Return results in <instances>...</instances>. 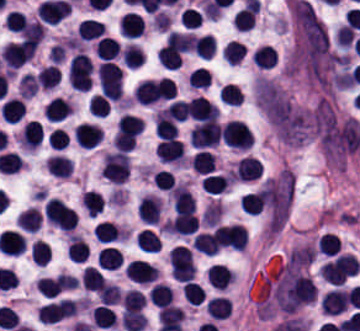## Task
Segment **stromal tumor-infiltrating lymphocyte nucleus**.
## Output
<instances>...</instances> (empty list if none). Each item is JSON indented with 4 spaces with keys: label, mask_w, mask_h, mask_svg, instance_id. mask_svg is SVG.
<instances>
[{
    "label": "stromal tumor-infiltrating lymphocyte nucleus",
    "mask_w": 360,
    "mask_h": 331,
    "mask_svg": "<svg viewBox=\"0 0 360 331\" xmlns=\"http://www.w3.org/2000/svg\"><path fill=\"white\" fill-rule=\"evenodd\" d=\"M147 299L154 306H163L172 300L169 285L161 282H154L149 289Z\"/></svg>",
    "instance_id": "26"
},
{
    "label": "stromal tumor-infiltrating lymphocyte nucleus",
    "mask_w": 360,
    "mask_h": 331,
    "mask_svg": "<svg viewBox=\"0 0 360 331\" xmlns=\"http://www.w3.org/2000/svg\"><path fill=\"white\" fill-rule=\"evenodd\" d=\"M36 89H37V83L33 75L25 72L19 76L17 82V90L20 96L28 99L34 95Z\"/></svg>",
    "instance_id": "44"
},
{
    "label": "stromal tumor-infiltrating lymphocyte nucleus",
    "mask_w": 360,
    "mask_h": 331,
    "mask_svg": "<svg viewBox=\"0 0 360 331\" xmlns=\"http://www.w3.org/2000/svg\"><path fill=\"white\" fill-rule=\"evenodd\" d=\"M105 26L103 22L93 19L91 17H84L80 20L75 28L76 35L81 39L92 40L100 37Z\"/></svg>",
    "instance_id": "15"
},
{
    "label": "stromal tumor-infiltrating lymphocyte nucleus",
    "mask_w": 360,
    "mask_h": 331,
    "mask_svg": "<svg viewBox=\"0 0 360 331\" xmlns=\"http://www.w3.org/2000/svg\"><path fill=\"white\" fill-rule=\"evenodd\" d=\"M117 30L121 36L134 38L143 31V22L137 13L125 11L117 22Z\"/></svg>",
    "instance_id": "11"
},
{
    "label": "stromal tumor-infiltrating lymphocyte nucleus",
    "mask_w": 360,
    "mask_h": 331,
    "mask_svg": "<svg viewBox=\"0 0 360 331\" xmlns=\"http://www.w3.org/2000/svg\"><path fill=\"white\" fill-rule=\"evenodd\" d=\"M253 63L261 68H269L275 64L276 55L272 49L267 45H260L252 51L250 55Z\"/></svg>",
    "instance_id": "30"
},
{
    "label": "stromal tumor-infiltrating lymphocyte nucleus",
    "mask_w": 360,
    "mask_h": 331,
    "mask_svg": "<svg viewBox=\"0 0 360 331\" xmlns=\"http://www.w3.org/2000/svg\"><path fill=\"white\" fill-rule=\"evenodd\" d=\"M181 56L179 51L161 47L159 49L158 63L165 68H179Z\"/></svg>",
    "instance_id": "45"
},
{
    "label": "stromal tumor-infiltrating lymphocyte nucleus",
    "mask_w": 360,
    "mask_h": 331,
    "mask_svg": "<svg viewBox=\"0 0 360 331\" xmlns=\"http://www.w3.org/2000/svg\"><path fill=\"white\" fill-rule=\"evenodd\" d=\"M36 48L37 43L22 40L5 43L0 50L1 61L9 69H16L34 54Z\"/></svg>",
    "instance_id": "1"
},
{
    "label": "stromal tumor-infiltrating lymphocyte nucleus",
    "mask_w": 360,
    "mask_h": 331,
    "mask_svg": "<svg viewBox=\"0 0 360 331\" xmlns=\"http://www.w3.org/2000/svg\"><path fill=\"white\" fill-rule=\"evenodd\" d=\"M37 81L41 89H49L58 84V69L55 64L41 67L37 71Z\"/></svg>",
    "instance_id": "34"
},
{
    "label": "stromal tumor-infiltrating lymphocyte nucleus",
    "mask_w": 360,
    "mask_h": 331,
    "mask_svg": "<svg viewBox=\"0 0 360 331\" xmlns=\"http://www.w3.org/2000/svg\"><path fill=\"white\" fill-rule=\"evenodd\" d=\"M221 101L229 105H240V89L237 83H223L218 88Z\"/></svg>",
    "instance_id": "38"
},
{
    "label": "stromal tumor-infiltrating lymphocyte nucleus",
    "mask_w": 360,
    "mask_h": 331,
    "mask_svg": "<svg viewBox=\"0 0 360 331\" xmlns=\"http://www.w3.org/2000/svg\"><path fill=\"white\" fill-rule=\"evenodd\" d=\"M120 56L122 64L127 68H138L144 59L141 47L130 42L121 50Z\"/></svg>",
    "instance_id": "24"
},
{
    "label": "stromal tumor-infiltrating lymphocyte nucleus",
    "mask_w": 360,
    "mask_h": 331,
    "mask_svg": "<svg viewBox=\"0 0 360 331\" xmlns=\"http://www.w3.org/2000/svg\"><path fill=\"white\" fill-rule=\"evenodd\" d=\"M161 209L160 198L150 195L141 196L139 200L138 218L141 222L157 224Z\"/></svg>",
    "instance_id": "10"
},
{
    "label": "stromal tumor-infiltrating lymphocyte nucleus",
    "mask_w": 360,
    "mask_h": 331,
    "mask_svg": "<svg viewBox=\"0 0 360 331\" xmlns=\"http://www.w3.org/2000/svg\"><path fill=\"white\" fill-rule=\"evenodd\" d=\"M216 47L214 36L200 35L195 36L192 41L194 53L202 59H209Z\"/></svg>",
    "instance_id": "27"
},
{
    "label": "stromal tumor-infiltrating lymphocyte nucleus",
    "mask_w": 360,
    "mask_h": 331,
    "mask_svg": "<svg viewBox=\"0 0 360 331\" xmlns=\"http://www.w3.org/2000/svg\"><path fill=\"white\" fill-rule=\"evenodd\" d=\"M80 283L96 292L102 287V273L93 266H86L81 274Z\"/></svg>",
    "instance_id": "35"
},
{
    "label": "stromal tumor-infiltrating lymphocyte nucleus",
    "mask_w": 360,
    "mask_h": 331,
    "mask_svg": "<svg viewBox=\"0 0 360 331\" xmlns=\"http://www.w3.org/2000/svg\"><path fill=\"white\" fill-rule=\"evenodd\" d=\"M219 125L216 121H202L191 129V144L197 148L214 146L218 142Z\"/></svg>",
    "instance_id": "2"
},
{
    "label": "stromal tumor-infiltrating lymphocyte nucleus",
    "mask_w": 360,
    "mask_h": 331,
    "mask_svg": "<svg viewBox=\"0 0 360 331\" xmlns=\"http://www.w3.org/2000/svg\"><path fill=\"white\" fill-rule=\"evenodd\" d=\"M261 208L260 189L249 191L242 195L241 210L245 213L257 215Z\"/></svg>",
    "instance_id": "36"
},
{
    "label": "stromal tumor-infiltrating lymphocyte nucleus",
    "mask_w": 360,
    "mask_h": 331,
    "mask_svg": "<svg viewBox=\"0 0 360 331\" xmlns=\"http://www.w3.org/2000/svg\"><path fill=\"white\" fill-rule=\"evenodd\" d=\"M209 285L217 290H224L234 279L230 270L221 263H213L206 272Z\"/></svg>",
    "instance_id": "12"
},
{
    "label": "stromal tumor-infiltrating lymphocyte nucleus",
    "mask_w": 360,
    "mask_h": 331,
    "mask_svg": "<svg viewBox=\"0 0 360 331\" xmlns=\"http://www.w3.org/2000/svg\"><path fill=\"white\" fill-rule=\"evenodd\" d=\"M144 295L137 289H129L122 294V312H139L143 307Z\"/></svg>",
    "instance_id": "29"
},
{
    "label": "stromal tumor-infiltrating lymphocyte nucleus",
    "mask_w": 360,
    "mask_h": 331,
    "mask_svg": "<svg viewBox=\"0 0 360 331\" xmlns=\"http://www.w3.org/2000/svg\"><path fill=\"white\" fill-rule=\"evenodd\" d=\"M119 45L111 36H103L94 43V55L101 60H112Z\"/></svg>",
    "instance_id": "23"
},
{
    "label": "stromal tumor-infiltrating lymphocyte nucleus",
    "mask_w": 360,
    "mask_h": 331,
    "mask_svg": "<svg viewBox=\"0 0 360 331\" xmlns=\"http://www.w3.org/2000/svg\"><path fill=\"white\" fill-rule=\"evenodd\" d=\"M120 321L125 331H139L147 322L143 314L134 311L125 312Z\"/></svg>",
    "instance_id": "41"
},
{
    "label": "stromal tumor-infiltrating lymphocyte nucleus",
    "mask_w": 360,
    "mask_h": 331,
    "mask_svg": "<svg viewBox=\"0 0 360 331\" xmlns=\"http://www.w3.org/2000/svg\"><path fill=\"white\" fill-rule=\"evenodd\" d=\"M69 101L60 96H53L43 108V116L49 120H63L71 111Z\"/></svg>",
    "instance_id": "14"
},
{
    "label": "stromal tumor-infiltrating lymphocyte nucleus",
    "mask_w": 360,
    "mask_h": 331,
    "mask_svg": "<svg viewBox=\"0 0 360 331\" xmlns=\"http://www.w3.org/2000/svg\"><path fill=\"white\" fill-rule=\"evenodd\" d=\"M80 199L89 217H96L105 207L102 194L91 189L84 191Z\"/></svg>",
    "instance_id": "18"
},
{
    "label": "stromal tumor-infiltrating lymphocyte nucleus",
    "mask_w": 360,
    "mask_h": 331,
    "mask_svg": "<svg viewBox=\"0 0 360 331\" xmlns=\"http://www.w3.org/2000/svg\"><path fill=\"white\" fill-rule=\"evenodd\" d=\"M134 242L142 252L146 253H156L160 248V241L156 234L145 228L136 233Z\"/></svg>",
    "instance_id": "25"
},
{
    "label": "stromal tumor-infiltrating lymphocyte nucleus",
    "mask_w": 360,
    "mask_h": 331,
    "mask_svg": "<svg viewBox=\"0 0 360 331\" xmlns=\"http://www.w3.org/2000/svg\"><path fill=\"white\" fill-rule=\"evenodd\" d=\"M207 316L216 320L228 318L232 313V301L225 296H212L206 301Z\"/></svg>",
    "instance_id": "13"
},
{
    "label": "stromal tumor-infiltrating lymphocyte nucleus",
    "mask_w": 360,
    "mask_h": 331,
    "mask_svg": "<svg viewBox=\"0 0 360 331\" xmlns=\"http://www.w3.org/2000/svg\"><path fill=\"white\" fill-rule=\"evenodd\" d=\"M72 161L59 154H53L46 159L44 168L57 178H66L71 171Z\"/></svg>",
    "instance_id": "17"
},
{
    "label": "stromal tumor-infiltrating lymphocyte nucleus",
    "mask_w": 360,
    "mask_h": 331,
    "mask_svg": "<svg viewBox=\"0 0 360 331\" xmlns=\"http://www.w3.org/2000/svg\"><path fill=\"white\" fill-rule=\"evenodd\" d=\"M94 237L100 243H108L122 238L119 228L111 221H97Z\"/></svg>",
    "instance_id": "20"
},
{
    "label": "stromal tumor-infiltrating lymphocyte nucleus",
    "mask_w": 360,
    "mask_h": 331,
    "mask_svg": "<svg viewBox=\"0 0 360 331\" xmlns=\"http://www.w3.org/2000/svg\"><path fill=\"white\" fill-rule=\"evenodd\" d=\"M175 120H183L187 114V101L173 99L162 112Z\"/></svg>",
    "instance_id": "47"
},
{
    "label": "stromal tumor-infiltrating lymphocyte nucleus",
    "mask_w": 360,
    "mask_h": 331,
    "mask_svg": "<svg viewBox=\"0 0 360 331\" xmlns=\"http://www.w3.org/2000/svg\"><path fill=\"white\" fill-rule=\"evenodd\" d=\"M187 117L196 121H216L213 104L197 94L187 100Z\"/></svg>",
    "instance_id": "6"
},
{
    "label": "stromal tumor-infiltrating lymphocyte nucleus",
    "mask_w": 360,
    "mask_h": 331,
    "mask_svg": "<svg viewBox=\"0 0 360 331\" xmlns=\"http://www.w3.org/2000/svg\"><path fill=\"white\" fill-rule=\"evenodd\" d=\"M88 108L92 116H106L109 109V100L106 95L94 93Z\"/></svg>",
    "instance_id": "46"
},
{
    "label": "stromal tumor-infiltrating lymphocyte nucleus",
    "mask_w": 360,
    "mask_h": 331,
    "mask_svg": "<svg viewBox=\"0 0 360 331\" xmlns=\"http://www.w3.org/2000/svg\"><path fill=\"white\" fill-rule=\"evenodd\" d=\"M319 307L327 315H340L346 310L344 289L332 288L319 298Z\"/></svg>",
    "instance_id": "7"
},
{
    "label": "stromal tumor-infiltrating lymphocyte nucleus",
    "mask_w": 360,
    "mask_h": 331,
    "mask_svg": "<svg viewBox=\"0 0 360 331\" xmlns=\"http://www.w3.org/2000/svg\"><path fill=\"white\" fill-rule=\"evenodd\" d=\"M154 132L159 138H170L177 134L176 123L172 117L155 115Z\"/></svg>",
    "instance_id": "32"
},
{
    "label": "stromal tumor-infiltrating lymphocyte nucleus",
    "mask_w": 360,
    "mask_h": 331,
    "mask_svg": "<svg viewBox=\"0 0 360 331\" xmlns=\"http://www.w3.org/2000/svg\"><path fill=\"white\" fill-rule=\"evenodd\" d=\"M219 245L213 232H200L192 242V249L200 254L216 255Z\"/></svg>",
    "instance_id": "19"
},
{
    "label": "stromal tumor-infiltrating lymphocyte nucleus",
    "mask_w": 360,
    "mask_h": 331,
    "mask_svg": "<svg viewBox=\"0 0 360 331\" xmlns=\"http://www.w3.org/2000/svg\"><path fill=\"white\" fill-rule=\"evenodd\" d=\"M155 153L163 163H180L184 155L180 140L174 138H162L155 148Z\"/></svg>",
    "instance_id": "9"
},
{
    "label": "stromal tumor-infiltrating lymphocyte nucleus",
    "mask_w": 360,
    "mask_h": 331,
    "mask_svg": "<svg viewBox=\"0 0 360 331\" xmlns=\"http://www.w3.org/2000/svg\"><path fill=\"white\" fill-rule=\"evenodd\" d=\"M262 164L255 156L244 155L234 164L232 176L239 180H254L259 178Z\"/></svg>",
    "instance_id": "8"
},
{
    "label": "stromal tumor-infiltrating lymphocyte nucleus",
    "mask_w": 360,
    "mask_h": 331,
    "mask_svg": "<svg viewBox=\"0 0 360 331\" xmlns=\"http://www.w3.org/2000/svg\"><path fill=\"white\" fill-rule=\"evenodd\" d=\"M17 227L22 231H36L39 225L38 211L32 206L17 215Z\"/></svg>",
    "instance_id": "31"
},
{
    "label": "stromal tumor-infiltrating lymphocyte nucleus",
    "mask_w": 360,
    "mask_h": 331,
    "mask_svg": "<svg viewBox=\"0 0 360 331\" xmlns=\"http://www.w3.org/2000/svg\"><path fill=\"white\" fill-rule=\"evenodd\" d=\"M121 291L116 284L103 283L98 294L97 299L100 305H113L119 301Z\"/></svg>",
    "instance_id": "37"
},
{
    "label": "stromal tumor-infiltrating lymphocyte nucleus",
    "mask_w": 360,
    "mask_h": 331,
    "mask_svg": "<svg viewBox=\"0 0 360 331\" xmlns=\"http://www.w3.org/2000/svg\"><path fill=\"white\" fill-rule=\"evenodd\" d=\"M191 166L196 174H209L213 171L216 162L211 152L199 151L192 159Z\"/></svg>",
    "instance_id": "28"
},
{
    "label": "stromal tumor-infiltrating lymphocyte nucleus",
    "mask_w": 360,
    "mask_h": 331,
    "mask_svg": "<svg viewBox=\"0 0 360 331\" xmlns=\"http://www.w3.org/2000/svg\"><path fill=\"white\" fill-rule=\"evenodd\" d=\"M101 138L102 130L97 124L81 121L74 126L73 139L85 148L96 147Z\"/></svg>",
    "instance_id": "4"
},
{
    "label": "stromal tumor-infiltrating lymphocyte nucleus",
    "mask_w": 360,
    "mask_h": 331,
    "mask_svg": "<svg viewBox=\"0 0 360 331\" xmlns=\"http://www.w3.org/2000/svg\"><path fill=\"white\" fill-rule=\"evenodd\" d=\"M30 255L33 263L43 267L51 256V250L48 244L36 238L30 244Z\"/></svg>",
    "instance_id": "33"
},
{
    "label": "stromal tumor-infiltrating lymphocyte nucleus",
    "mask_w": 360,
    "mask_h": 331,
    "mask_svg": "<svg viewBox=\"0 0 360 331\" xmlns=\"http://www.w3.org/2000/svg\"><path fill=\"white\" fill-rule=\"evenodd\" d=\"M245 45L238 40H231L223 47L222 58L229 64H237L244 55Z\"/></svg>",
    "instance_id": "40"
},
{
    "label": "stromal tumor-infiltrating lymphocyte nucleus",
    "mask_w": 360,
    "mask_h": 331,
    "mask_svg": "<svg viewBox=\"0 0 360 331\" xmlns=\"http://www.w3.org/2000/svg\"><path fill=\"white\" fill-rule=\"evenodd\" d=\"M222 213V203L217 201L208 203L201 214V225L213 226Z\"/></svg>",
    "instance_id": "43"
},
{
    "label": "stromal tumor-infiltrating lymphocyte nucleus",
    "mask_w": 360,
    "mask_h": 331,
    "mask_svg": "<svg viewBox=\"0 0 360 331\" xmlns=\"http://www.w3.org/2000/svg\"><path fill=\"white\" fill-rule=\"evenodd\" d=\"M89 246L84 238L69 235L67 242V258L71 262H80L87 257Z\"/></svg>",
    "instance_id": "21"
},
{
    "label": "stromal tumor-infiltrating lymphocyte nucleus",
    "mask_w": 360,
    "mask_h": 331,
    "mask_svg": "<svg viewBox=\"0 0 360 331\" xmlns=\"http://www.w3.org/2000/svg\"><path fill=\"white\" fill-rule=\"evenodd\" d=\"M96 262L104 269H114L120 266L122 254L116 247H102L96 254Z\"/></svg>",
    "instance_id": "22"
},
{
    "label": "stromal tumor-infiltrating lymphocyte nucleus",
    "mask_w": 360,
    "mask_h": 331,
    "mask_svg": "<svg viewBox=\"0 0 360 331\" xmlns=\"http://www.w3.org/2000/svg\"><path fill=\"white\" fill-rule=\"evenodd\" d=\"M123 271L127 279L139 284H148L154 281L158 274L151 264L139 259H132L125 265Z\"/></svg>",
    "instance_id": "3"
},
{
    "label": "stromal tumor-infiltrating lymphocyte nucleus",
    "mask_w": 360,
    "mask_h": 331,
    "mask_svg": "<svg viewBox=\"0 0 360 331\" xmlns=\"http://www.w3.org/2000/svg\"><path fill=\"white\" fill-rule=\"evenodd\" d=\"M48 146L53 151H61L68 146L69 136L61 127H54L47 136Z\"/></svg>",
    "instance_id": "42"
},
{
    "label": "stromal tumor-infiltrating lymphocyte nucleus",
    "mask_w": 360,
    "mask_h": 331,
    "mask_svg": "<svg viewBox=\"0 0 360 331\" xmlns=\"http://www.w3.org/2000/svg\"><path fill=\"white\" fill-rule=\"evenodd\" d=\"M209 85V74L203 68H197L189 72V86L194 88H206Z\"/></svg>",
    "instance_id": "48"
},
{
    "label": "stromal tumor-infiltrating lymphocyte nucleus",
    "mask_w": 360,
    "mask_h": 331,
    "mask_svg": "<svg viewBox=\"0 0 360 331\" xmlns=\"http://www.w3.org/2000/svg\"><path fill=\"white\" fill-rule=\"evenodd\" d=\"M232 179L228 172L205 175L202 190L207 194H221L230 185Z\"/></svg>",
    "instance_id": "16"
},
{
    "label": "stromal tumor-infiltrating lymphocyte nucleus",
    "mask_w": 360,
    "mask_h": 331,
    "mask_svg": "<svg viewBox=\"0 0 360 331\" xmlns=\"http://www.w3.org/2000/svg\"><path fill=\"white\" fill-rule=\"evenodd\" d=\"M184 299L191 305H198L204 296V291L199 284L192 280H187L181 286Z\"/></svg>",
    "instance_id": "39"
},
{
    "label": "stromal tumor-infiltrating lymphocyte nucleus",
    "mask_w": 360,
    "mask_h": 331,
    "mask_svg": "<svg viewBox=\"0 0 360 331\" xmlns=\"http://www.w3.org/2000/svg\"><path fill=\"white\" fill-rule=\"evenodd\" d=\"M42 137L43 129L40 122L27 120L17 135L18 146L31 152L39 145Z\"/></svg>",
    "instance_id": "5"
}]
</instances>
